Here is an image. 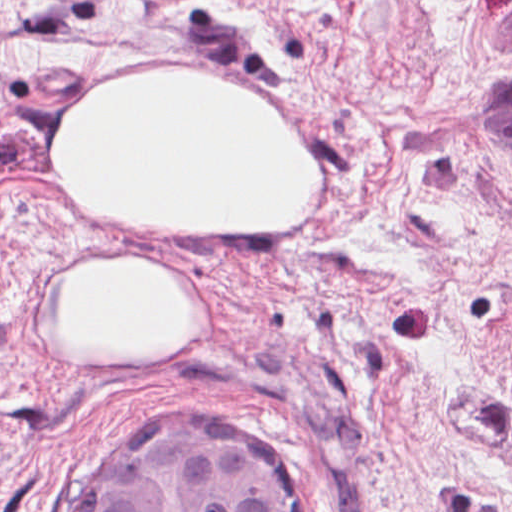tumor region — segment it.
<instances>
[{
	"instance_id": "e687c5a6",
	"label": "tumor region",
	"mask_w": 512,
	"mask_h": 512,
	"mask_svg": "<svg viewBox=\"0 0 512 512\" xmlns=\"http://www.w3.org/2000/svg\"><path fill=\"white\" fill-rule=\"evenodd\" d=\"M167 423L125 451L99 512H313L274 462L244 441L191 423Z\"/></svg>"
}]
</instances>
